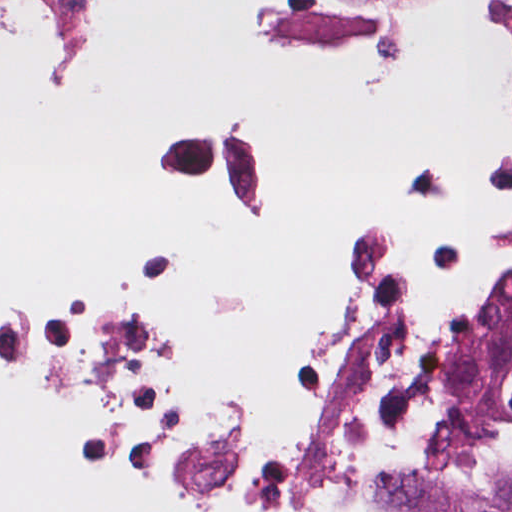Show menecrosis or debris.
Here are the masks:
<instances>
[{
    "mask_svg": "<svg viewBox=\"0 0 512 512\" xmlns=\"http://www.w3.org/2000/svg\"><path fill=\"white\" fill-rule=\"evenodd\" d=\"M508 132L312 212L241 117L150 128L184 192L253 244L254 289L59 254L0 261V466L56 512H390L434 477L512 483L484 385L512 329Z\"/></svg>",
    "mask_w": 512,
    "mask_h": 512,
    "instance_id": "necrosis-or-debris-1",
    "label": "necrosis or debris"
}]
</instances>
